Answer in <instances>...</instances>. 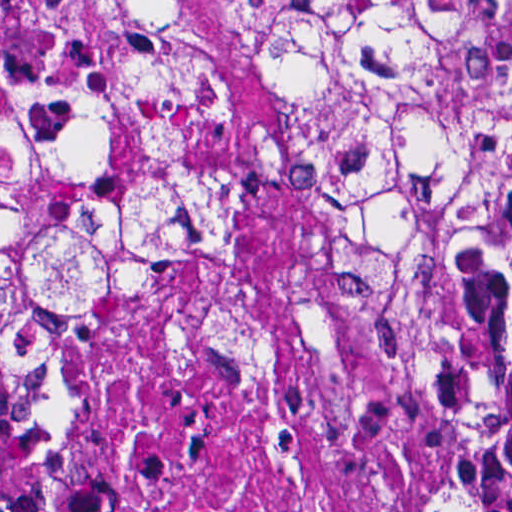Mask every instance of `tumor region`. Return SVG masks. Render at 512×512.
<instances>
[{"label": "tumor region", "mask_w": 512, "mask_h": 512, "mask_svg": "<svg viewBox=\"0 0 512 512\" xmlns=\"http://www.w3.org/2000/svg\"><path fill=\"white\" fill-rule=\"evenodd\" d=\"M258 3L300 101L223 128L161 0H0V512L82 417L77 338L232 269L280 178L435 425L409 512H512V0Z\"/></svg>", "instance_id": "obj_1"}]
</instances>
